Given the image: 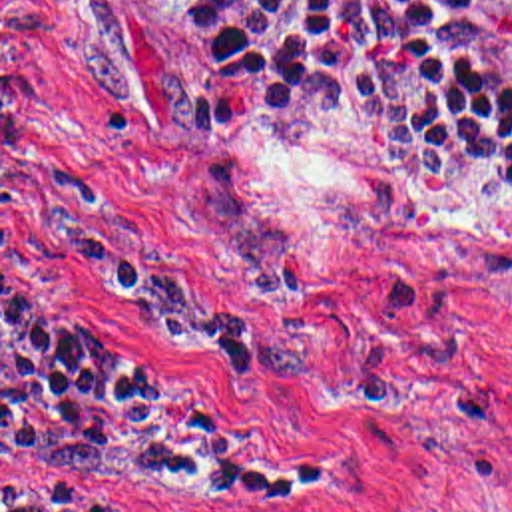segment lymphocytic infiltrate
I'll use <instances>...</instances> for the list:
<instances>
[{
  "label": "lymphocytic infiltrate",
  "mask_w": 512,
  "mask_h": 512,
  "mask_svg": "<svg viewBox=\"0 0 512 512\" xmlns=\"http://www.w3.org/2000/svg\"><path fill=\"white\" fill-rule=\"evenodd\" d=\"M179 53L239 103L372 105L420 167L512 171V0H173ZM197 384L2 298V474L275 480ZM2 512H92L64 484Z\"/></svg>",
  "instance_id": "1"
}]
</instances>
